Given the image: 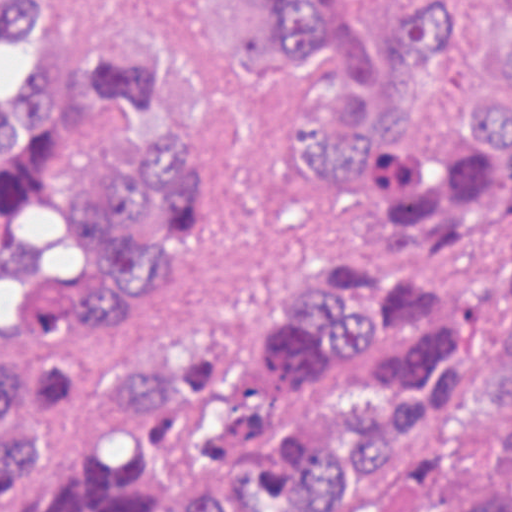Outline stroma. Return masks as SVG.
Segmentation results:
<instances>
[{
    "instance_id": "35a3bbf8",
    "label": "stroma",
    "mask_w": 512,
    "mask_h": 512,
    "mask_svg": "<svg viewBox=\"0 0 512 512\" xmlns=\"http://www.w3.org/2000/svg\"><path fill=\"white\" fill-rule=\"evenodd\" d=\"M335 1L347 28L373 33L434 10L457 33L425 108L455 111L472 94H512L497 43L512 29V0ZM103 36H146L181 60L189 123L212 160L181 279L160 287L145 327L119 332L173 353L208 348L258 319L279 282L342 251L345 204L300 189L288 130L327 72L277 50L259 0H50L36 37L0 39V93L30 68L72 64ZM0 353L34 357L1 338Z\"/></svg>"
}]
</instances>
